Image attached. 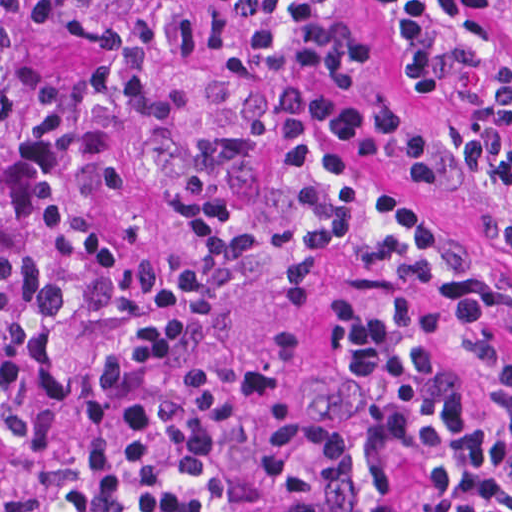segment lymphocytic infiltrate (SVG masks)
<instances>
[{
  "instance_id": "1",
  "label": "lymphocytic infiltrate",
  "mask_w": 512,
  "mask_h": 512,
  "mask_svg": "<svg viewBox=\"0 0 512 512\" xmlns=\"http://www.w3.org/2000/svg\"><path fill=\"white\" fill-rule=\"evenodd\" d=\"M395 70L467 94L498 56L482 0H378ZM461 163L493 256L426 199L432 129L362 82L345 0H182L123 172L93 227L54 493L193 488L240 425L259 334L340 269L429 289L333 309L305 395L236 512H512V109Z\"/></svg>"
}]
</instances>
